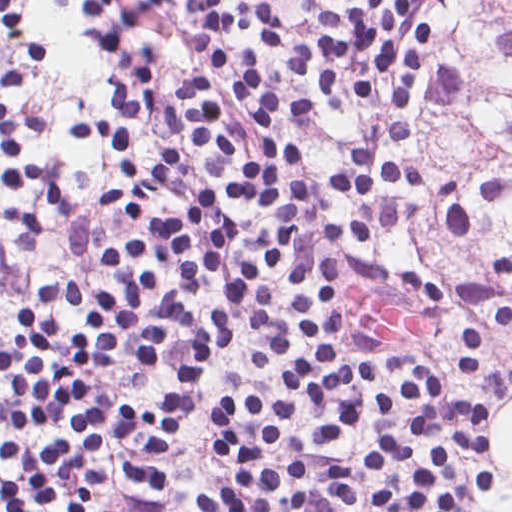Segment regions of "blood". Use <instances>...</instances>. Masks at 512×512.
I'll list each match as a JSON object with an SVG mask.
<instances>
[{"label": "blood", "instance_id": "1", "mask_svg": "<svg viewBox=\"0 0 512 512\" xmlns=\"http://www.w3.org/2000/svg\"><path fill=\"white\" fill-rule=\"evenodd\" d=\"M347 319L361 331L379 337H417L426 332L428 321L414 319L378 298L353 288Z\"/></svg>", "mask_w": 512, "mask_h": 512}]
</instances>
